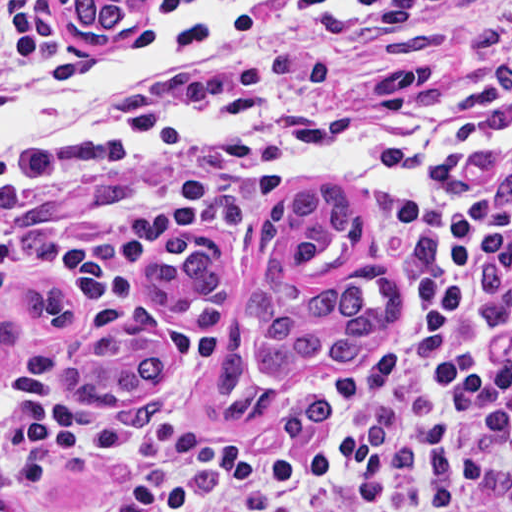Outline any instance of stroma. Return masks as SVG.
I'll list each match as a JSON object with an SVG mask.
<instances>
[{
    "instance_id": "1",
    "label": "stroma",
    "mask_w": 512,
    "mask_h": 512,
    "mask_svg": "<svg viewBox=\"0 0 512 512\" xmlns=\"http://www.w3.org/2000/svg\"><path fill=\"white\" fill-rule=\"evenodd\" d=\"M187 1L150 0L146 21ZM291 1L265 23L244 66L213 90L200 107L234 90L261 66ZM10 25H35L76 52L78 71L55 87L79 81L114 52L85 51L74 45L52 0L0 2V31ZM434 87L429 73H410L397 78L389 99L309 101L272 113L208 121L290 124L364 108L409 110L418 120ZM209 173L186 164H108L87 170H58L0 182V206L9 212L22 256L35 257L45 249L88 235L125 230L143 216L156 197L188 187ZM223 178L225 197L220 206L207 220L172 236L214 241L227 266L250 280L259 273L264 228L283 196H264ZM416 194L406 199H357L360 225L351 258L341 268L302 274L292 282L300 291H322L359 276H394L397 314L367 362L317 358L288 376L261 377L253 367L256 344L243 297L237 295L222 318L185 315L218 334L232 324L240 327L247 342L250 384L287 395H324L328 399L326 422L336 419L351 396L403 340L411 323L402 274V238ZM143 263L139 272L141 293L166 306L148 287ZM40 285L75 288L68 276L45 268L22 273L13 282L0 284V324L31 321L17 293ZM136 310L150 309L128 295L107 302L97 337L111 322ZM159 323L161 338L170 344V364L164 378L143 395L116 403H77L64 392L52 407L40 413L12 411L0 404V512H187L173 485L143 468L63 446L52 431L65 425L151 428L179 452L209 464L253 456L296 436H309L284 435L263 424L238 430L226 427L219 416L211 368L202 374L191 370ZM60 338L42 336L1 356L0 391L17 371L52 351Z\"/></svg>"
}]
</instances>
